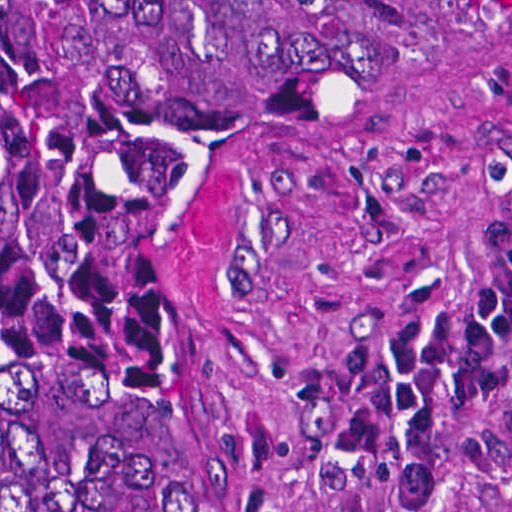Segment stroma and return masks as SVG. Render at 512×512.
I'll return each instance as SVG.
<instances>
[{
	"instance_id": "35a3bbf8",
	"label": "stroma",
	"mask_w": 512,
	"mask_h": 512,
	"mask_svg": "<svg viewBox=\"0 0 512 512\" xmlns=\"http://www.w3.org/2000/svg\"><path fill=\"white\" fill-rule=\"evenodd\" d=\"M508 244L512 22L464 32L227 208L188 344V512H512V337L487 400L439 391L426 508L367 501L325 445L392 335L468 299Z\"/></svg>"
}]
</instances>
